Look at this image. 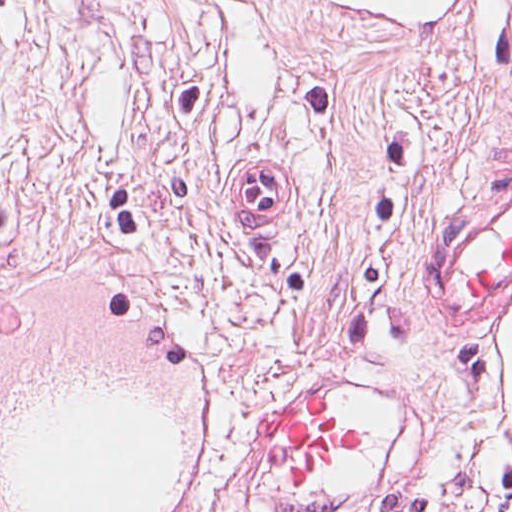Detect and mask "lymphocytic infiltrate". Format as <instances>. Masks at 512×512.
Segmentation results:
<instances>
[{"mask_svg":"<svg viewBox=\"0 0 512 512\" xmlns=\"http://www.w3.org/2000/svg\"><path fill=\"white\" fill-rule=\"evenodd\" d=\"M389 505L393 512H512V482H505L483 496L398 501Z\"/></svg>","mask_w":512,"mask_h":512,"instance_id":"obj_1","label":"lymphocytic infiltrate"}]
</instances>
